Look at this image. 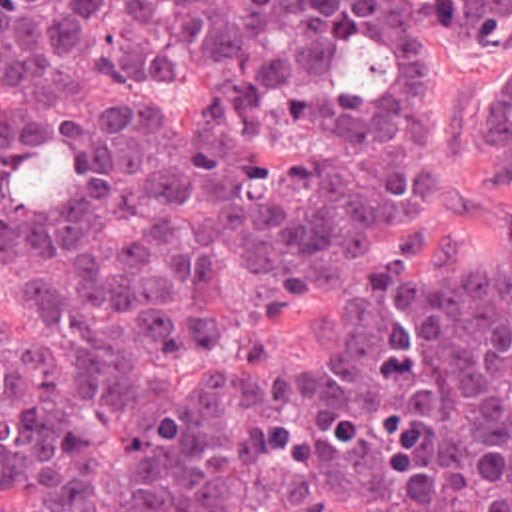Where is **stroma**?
I'll list each match as a JSON object with an SVG mask.
<instances>
[{
    "mask_svg": "<svg viewBox=\"0 0 512 512\" xmlns=\"http://www.w3.org/2000/svg\"><path fill=\"white\" fill-rule=\"evenodd\" d=\"M510 48H464L440 40L430 46V112L392 139L380 161L412 151L430 187L422 203L382 223L384 245L398 247L418 231L444 253L472 261H500L512 225V171L480 143V106L488 74ZM0 299L23 331H46L44 291L19 257L0 221ZM278 363L288 371L324 369L340 357V313L328 291L294 287L276 297L260 319ZM0 512H29L13 469L0 463Z\"/></svg>",
    "mask_w": 512,
    "mask_h": 512,
    "instance_id": "obj_1",
    "label": "stroma"
}]
</instances>
